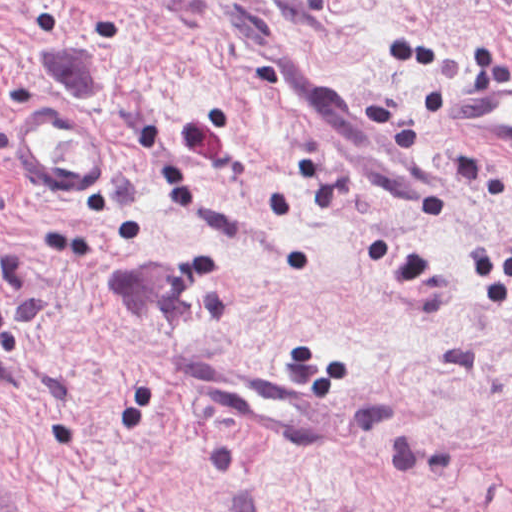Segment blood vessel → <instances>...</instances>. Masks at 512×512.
<instances>
[{
    "mask_svg": "<svg viewBox=\"0 0 512 512\" xmlns=\"http://www.w3.org/2000/svg\"><path fill=\"white\" fill-rule=\"evenodd\" d=\"M281 97L321 137L346 176L390 222L433 229L455 212V165L328 75L278 64ZM441 126L512 146V73L483 75L434 115ZM6 279L0 269V312ZM189 394L285 442L334 446L339 410L319 388L274 369L173 359Z\"/></svg>",
    "mask_w": 512,
    "mask_h": 512,
    "instance_id": "1",
    "label": "blood vessel"
}]
</instances>
